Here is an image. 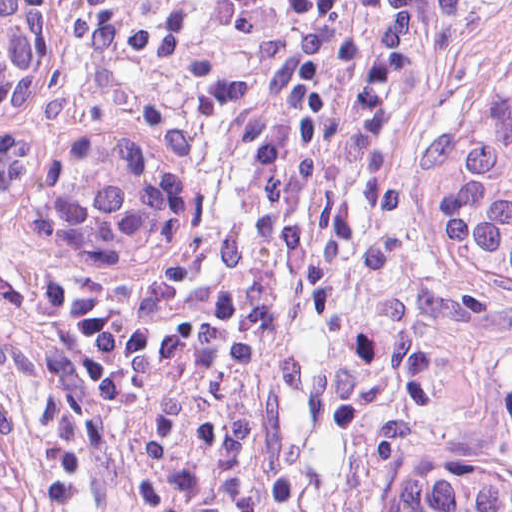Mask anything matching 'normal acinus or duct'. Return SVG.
I'll return each instance as SVG.
<instances>
[{
    "mask_svg": "<svg viewBox=\"0 0 512 512\" xmlns=\"http://www.w3.org/2000/svg\"><path fill=\"white\" fill-rule=\"evenodd\" d=\"M50 76L43 0H0V121L39 104ZM128 130L61 131L42 142L0 132V196L38 189L44 229L70 266H124L158 231V164ZM0 512H42L27 438L0 399Z\"/></svg>",
    "mask_w": 512,
    "mask_h": 512,
    "instance_id": "1",
    "label": "normal acinus or duct"
}]
</instances>
